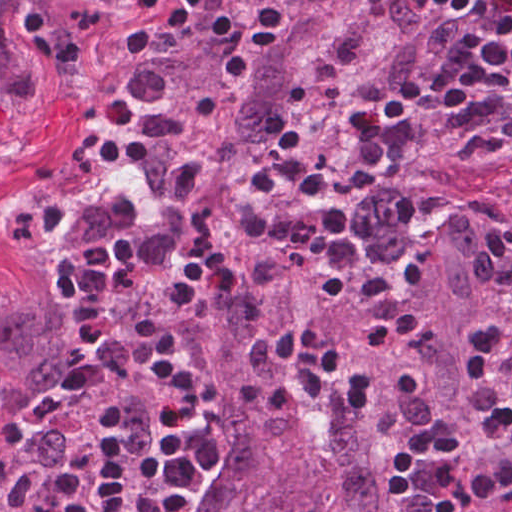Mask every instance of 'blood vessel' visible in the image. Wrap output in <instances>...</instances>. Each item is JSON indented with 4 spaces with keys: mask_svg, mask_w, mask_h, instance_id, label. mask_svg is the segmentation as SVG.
<instances>
[{
    "mask_svg": "<svg viewBox=\"0 0 512 512\" xmlns=\"http://www.w3.org/2000/svg\"><path fill=\"white\" fill-rule=\"evenodd\" d=\"M479 512H512V492L496 499Z\"/></svg>",
    "mask_w": 512,
    "mask_h": 512,
    "instance_id": "blood-vessel-1",
    "label": "blood vessel"
}]
</instances>
